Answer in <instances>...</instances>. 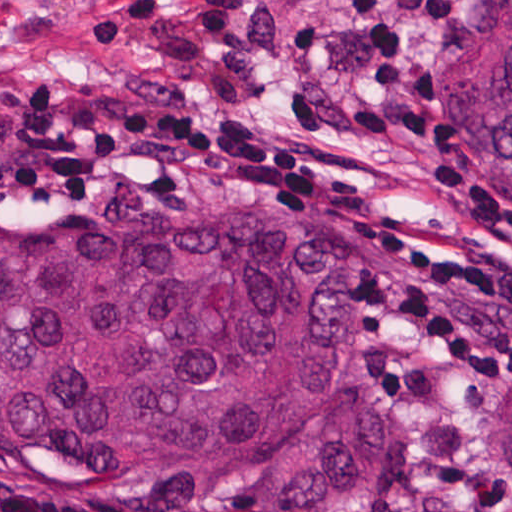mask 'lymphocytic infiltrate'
<instances>
[{"label": "lymphocytic infiltrate", "mask_w": 512, "mask_h": 512, "mask_svg": "<svg viewBox=\"0 0 512 512\" xmlns=\"http://www.w3.org/2000/svg\"><path fill=\"white\" fill-rule=\"evenodd\" d=\"M369 53L359 120L375 140L433 146L427 81L406 61L408 22L447 25L453 0H335ZM466 220L487 227L478 261L359 225L370 267L361 315L392 356L478 381H512V203L464 166L430 168ZM354 182L347 156L298 135L251 128L197 92L109 88L64 102L47 88L0 104V194L98 197L148 191H317ZM0 512H131L0 493Z\"/></svg>", "instance_id": "lymphocytic-infiltrate-1"}]
</instances>
